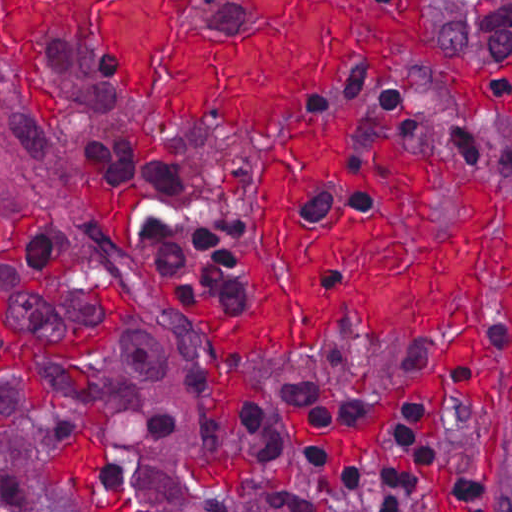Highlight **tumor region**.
I'll return each mask as SVG.
<instances>
[{
  "instance_id": "1",
  "label": "tumor region",
  "mask_w": 512,
  "mask_h": 512,
  "mask_svg": "<svg viewBox=\"0 0 512 512\" xmlns=\"http://www.w3.org/2000/svg\"><path fill=\"white\" fill-rule=\"evenodd\" d=\"M253 0H189L201 25L220 37H244ZM452 54L476 64L512 61V0H434Z\"/></svg>"
}]
</instances>
